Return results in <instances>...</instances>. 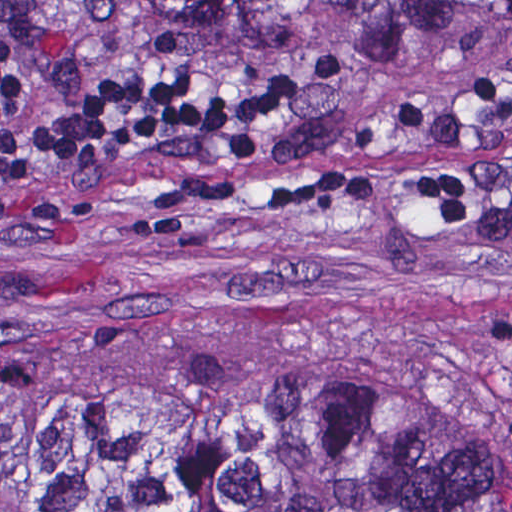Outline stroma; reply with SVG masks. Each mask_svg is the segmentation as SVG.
<instances>
[{
    "mask_svg": "<svg viewBox=\"0 0 512 512\" xmlns=\"http://www.w3.org/2000/svg\"><path fill=\"white\" fill-rule=\"evenodd\" d=\"M51 43L84 86L227 74L268 109L236 149L137 129L0 194V363L98 378L304 360L422 402L512 394L509 0H432L358 37L164 34L127 0H58ZM338 159L472 165L474 219L450 229L403 192L252 208Z\"/></svg>",
    "mask_w": 512,
    "mask_h": 512,
    "instance_id": "obj_1",
    "label": "stroma"
}]
</instances>
